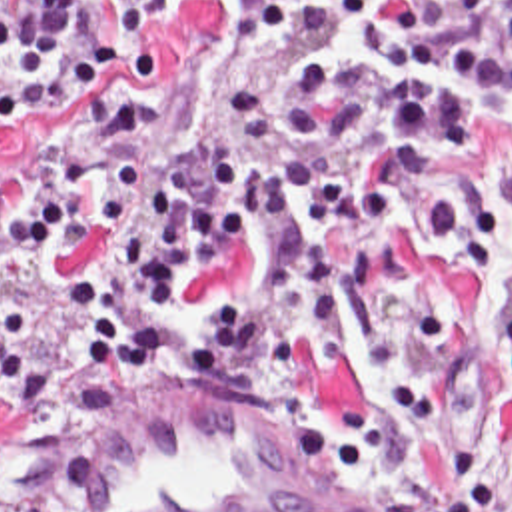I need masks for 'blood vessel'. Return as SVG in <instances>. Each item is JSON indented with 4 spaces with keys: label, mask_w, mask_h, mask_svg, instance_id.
<instances>
[{
    "label": "blood vessel",
    "mask_w": 512,
    "mask_h": 512,
    "mask_svg": "<svg viewBox=\"0 0 512 512\" xmlns=\"http://www.w3.org/2000/svg\"><path fill=\"white\" fill-rule=\"evenodd\" d=\"M388 485L310 428L190 396L72 448L44 512H394Z\"/></svg>",
    "instance_id": "blood-vessel-1"
}]
</instances>
